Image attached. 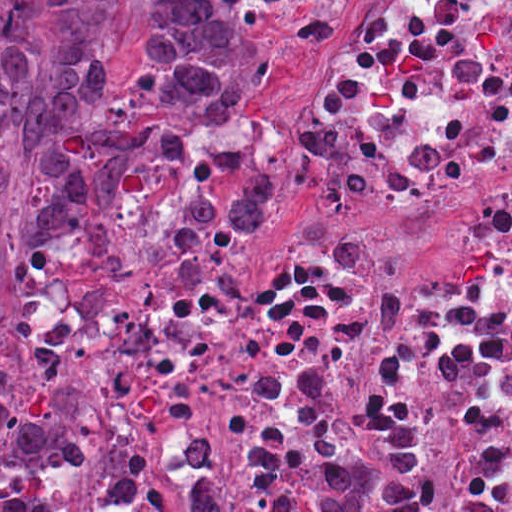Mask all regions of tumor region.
Returning a JSON list of instances; mask_svg holds the SVG:
<instances>
[{
    "label": "tumor region",
    "instance_id": "1",
    "mask_svg": "<svg viewBox=\"0 0 512 512\" xmlns=\"http://www.w3.org/2000/svg\"><path fill=\"white\" fill-rule=\"evenodd\" d=\"M300 4L0 0V146L28 168L19 237L127 266L162 237L208 245L250 228L272 200L253 125L272 87L263 23ZM359 453L329 457L315 496L266 512H430L418 419L396 426L388 460ZM79 478L78 438L24 403L0 356V512H78ZM196 512H234L229 492L205 478Z\"/></svg>",
    "mask_w": 512,
    "mask_h": 512
}]
</instances>
